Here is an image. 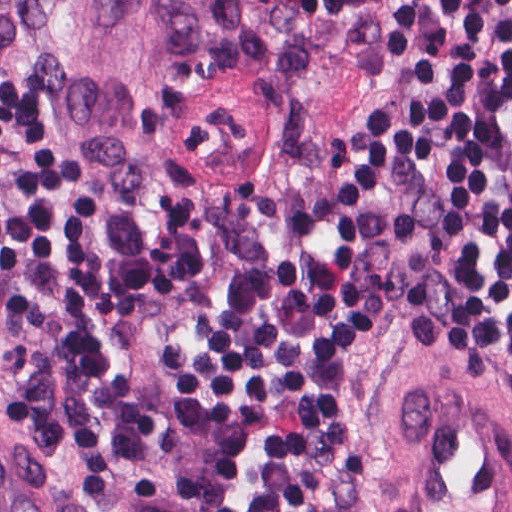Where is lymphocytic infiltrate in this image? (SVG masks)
Wrapping results in <instances>:
<instances>
[{
  "mask_svg": "<svg viewBox=\"0 0 512 512\" xmlns=\"http://www.w3.org/2000/svg\"><path fill=\"white\" fill-rule=\"evenodd\" d=\"M398 142L335 200L198 358L194 402L252 446L266 512H340L342 411L363 351L437 342L512 371V0H397ZM0 284L47 320L3 417L67 452L98 505L163 447L155 406L91 347L99 217L73 121L0 88ZM430 347V346H429Z\"/></svg>",
  "mask_w": 512,
  "mask_h": 512,
  "instance_id": "lymphocytic-infiltrate-1",
  "label": "lymphocytic infiltrate"
}]
</instances>
